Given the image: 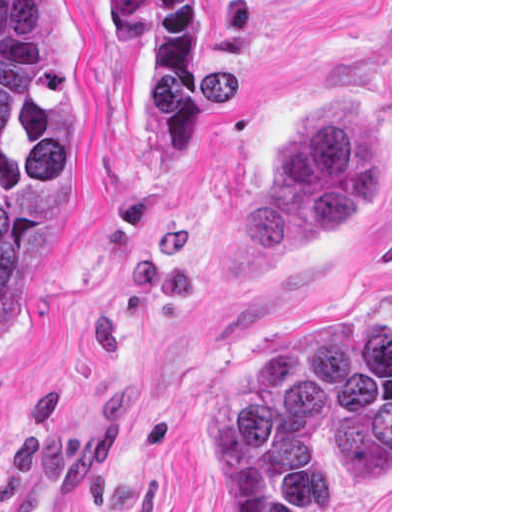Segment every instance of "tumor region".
<instances>
[{"label":"tumor region","instance_id":"e687c5a6","mask_svg":"<svg viewBox=\"0 0 512 512\" xmlns=\"http://www.w3.org/2000/svg\"><path fill=\"white\" fill-rule=\"evenodd\" d=\"M140 69L143 113L169 172L198 139L208 1H96ZM81 105V44L66 1H0V343L21 323L52 247V172ZM381 195V142L363 107L312 111L219 244L225 280L361 222ZM364 491L390 489V312L301 319L241 350L212 393L219 512H304L309 459Z\"/></svg>","mask_w":512,"mask_h":512}]
</instances>
